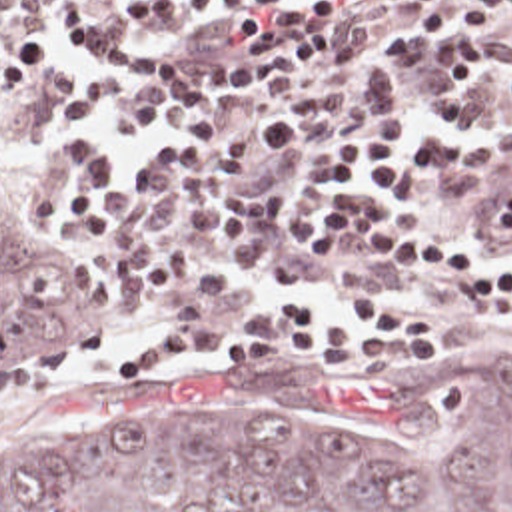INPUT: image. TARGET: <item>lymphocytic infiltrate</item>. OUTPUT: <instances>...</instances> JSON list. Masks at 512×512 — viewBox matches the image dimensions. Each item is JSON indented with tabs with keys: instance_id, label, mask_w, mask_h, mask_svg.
<instances>
[{
	"instance_id": "lymphocytic-infiltrate-1",
	"label": "lymphocytic infiltrate",
	"mask_w": 512,
	"mask_h": 512,
	"mask_svg": "<svg viewBox=\"0 0 512 512\" xmlns=\"http://www.w3.org/2000/svg\"><path fill=\"white\" fill-rule=\"evenodd\" d=\"M425 11L418 29L449 33L437 47L441 75L431 95L435 119L459 117L469 125L473 89L481 73H495V113L512 109V39L495 53L483 31L469 27L512 11V0H400ZM210 17L240 43V57H174L144 35L176 31L186 17ZM340 0H144L122 23L60 21L66 35L84 43L110 73L142 61H168L178 71L172 107H242L280 93L324 69L362 55V37L334 29ZM56 61V39L0 21V91L36 85ZM254 131L238 121H190L172 133L174 154L130 164V176L168 180L180 188L272 206L306 220V182L266 180L262 168L306 150V125L298 117H258ZM439 146L437 125H423L408 142L402 123L364 119L348 135L316 148L314 162L336 190L314 226L332 244L334 264L342 244L386 262L394 270L433 274L459 284L512 316V262L473 248L404 206ZM252 330L228 342L236 364H278L288 346H310L326 364L354 356L374 364H431L445 354V322L384 294L338 304L322 296H292L252 316ZM202 346V334L164 338L126 358L124 372L176 362Z\"/></svg>"
}]
</instances>
